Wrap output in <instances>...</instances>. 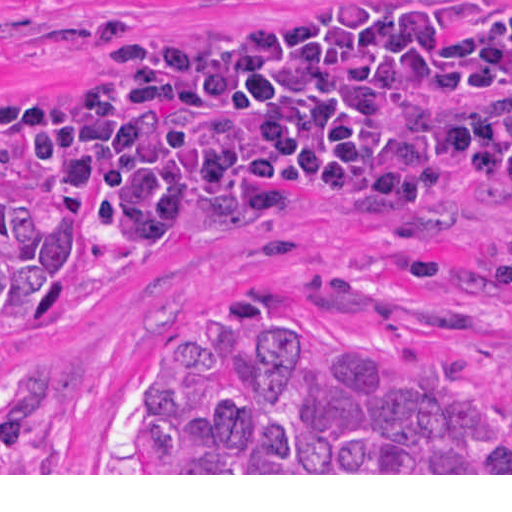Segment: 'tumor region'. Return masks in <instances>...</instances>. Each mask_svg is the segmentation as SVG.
<instances>
[{
  "label": "tumor region",
  "instance_id": "obj_1",
  "mask_svg": "<svg viewBox=\"0 0 512 512\" xmlns=\"http://www.w3.org/2000/svg\"><path fill=\"white\" fill-rule=\"evenodd\" d=\"M69 218L0 186V302L72 307ZM42 352L0 339V473L49 411ZM123 473H512V417L376 347L333 337L277 288L178 312L143 384Z\"/></svg>",
  "mask_w": 512,
  "mask_h": 512
}]
</instances>
